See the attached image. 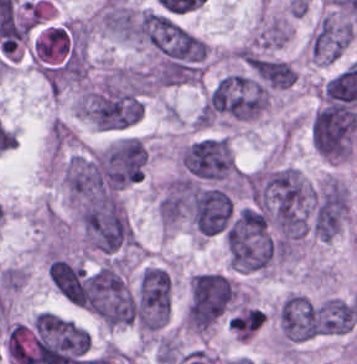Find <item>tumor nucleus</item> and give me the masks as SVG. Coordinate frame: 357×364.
Masks as SVG:
<instances>
[{"label":"tumor nucleus","instance_id":"tumor-nucleus-1","mask_svg":"<svg viewBox=\"0 0 357 364\" xmlns=\"http://www.w3.org/2000/svg\"><path fill=\"white\" fill-rule=\"evenodd\" d=\"M74 292L77 302L100 321L132 323L134 301L112 263L79 275Z\"/></svg>","mask_w":357,"mask_h":364},{"label":"tumor nucleus","instance_id":"tumor-nucleus-2","mask_svg":"<svg viewBox=\"0 0 357 364\" xmlns=\"http://www.w3.org/2000/svg\"><path fill=\"white\" fill-rule=\"evenodd\" d=\"M356 124L354 110L344 103L324 104L310 121L312 147L330 158H346Z\"/></svg>","mask_w":357,"mask_h":364},{"label":"tumor nucleus","instance_id":"tumor-nucleus-3","mask_svg":"<svg viewBox=\"0 0 357 364\" xmlns=\"http://www.w3.org/2000/svg\"><path fill=\"white\" fill-rule=\"evenodd\" d=\"M234 287L224 273L203 271L191 277L188 324H211L228 308Z\"/></svg>","mask_w":357,"mask_h":364},{"label":"tumor nucleus","instance_id":"tumor-nucleus-4","mask_svg":"<svg viewBox=\"0 0 357 364\" xmlns=\"http://www.w3.org/2000/svg\"><path fill=\"white\" fill-rule=\"evenodd\" d=\"M181 168L197 180L220 181L233 174L234 165L223 137H203L183 147Z\"/></svg>","mask_w":357,"mask_h":364},{"label":"tumor nucleus","instance_id":"tumor-nucleus-5","mask_svg":"<svg viewBox=\"0 0 357 364\" xmlns=\"http://www.w3.org/2000/svg\"><path fill=\"white\" fill-rule=\"evenodd\" d=\"M169 310L168 273L161 267L147 266L137 286L133 321L147 330L161 327Z\"/></svg>","mask_w":357,"mask_h":364},{"label":"tumor nucleus","instance_id":"tumor-nucleus-6","mask_svg":"<svg viewBox=\"0 0 357 364\" xmlns=\"http://www.w3.org/2000/svg\"><path fill=\"white\" fill-rule=\"evenodd\" d=\"M145 149L138 139L123 136L109 144L97 159V169L108 187L135 183L141 175Z\"/></svg>","mask_w":357,"mask_h":364},{"label":"tumor nucleus","instance_id":"tumor-nucleus-7","mask_svg":"<svg viewBox=\"0 0 357 364\" xmlns=\"http://www.w3.org/2000/svg\"><path fill=\"white\" fill-rule=\"evenodd\" d=\"M345 211L343 185L328 177L311 195L307 227L317 238L329 240L339 230Z\"/></svg>","mask_w":357,"mask_h":364},{"label":"tumor nucleus","instance_id":"tumor-nucleus-8","mask_svg":"<svg viewBox=\"0 0 357 364\" xmlns=\"http://www.w3.org/2000/svg\"><path fill=\"white\" fill-rule=\"evenodd\" d=\"M193 220L204 232L222 230L229 219V195L217 188H195L191 193Z\"/></svg>","mask_w":357,"mask_h":364},{"label":"tumor nucleus","instance_id":"tumor-nucleus-9","mask_svg":"<svg viewBox=\"0 0 357 364\" xmlns=\"http://www.w3.org/2000/svg\"><path fill=\"white\" fill-rule=\"evenodd\" d=\"M351 42L349 24L321 19L310 36L312 60L334 61Z\"/></svg>","mask_w":357,"mask_h":364},{"label":"tumor nucleus","instance_id":"tumor-nucleus-10","mask_svg":"<svg viewBox=\"0 0 357 364\" xmlns=\"http://www.w3.org/2000/svg\"><path fill=\"white\" fill-rule=\"evenodd\" d=\"M245 62L260 87L285 88L295 73L284 60L249 55Z\"/></svg>","mask_w":357,"mask_h":364}]
</instances>
